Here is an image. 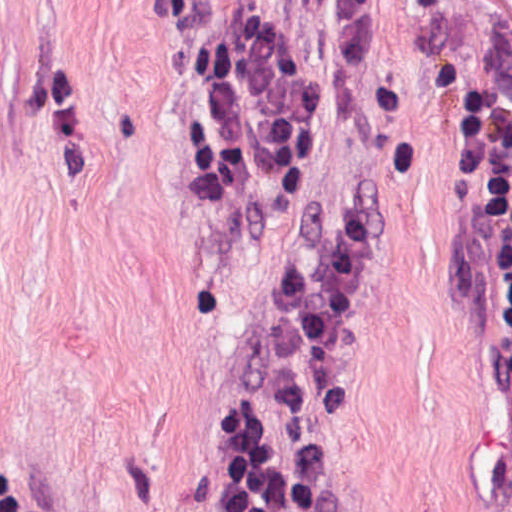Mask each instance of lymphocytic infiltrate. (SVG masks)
Instances as JSON below:
<instances>
[{
  "label": "lymphocytic infiltrate",
  "mask_w": 512,
  "mask_h": 512,
  "mask_svg": "<svg viewBox=\"0 0 512 512\" xmlns=\"http://www.w3.org/2000/svg\"><path fill=\"white\" fill-rule=\"evenodd\" d=\"M372 0H171L176 125L219 232L291 207L333 74ZM450 250L500 333L512 406V66L464 145ZM386 259L377 185L296 248L207 439L231 512H342L328 411Z\"/></svg>",
  "instance_id": "1"
}]
</instances>
